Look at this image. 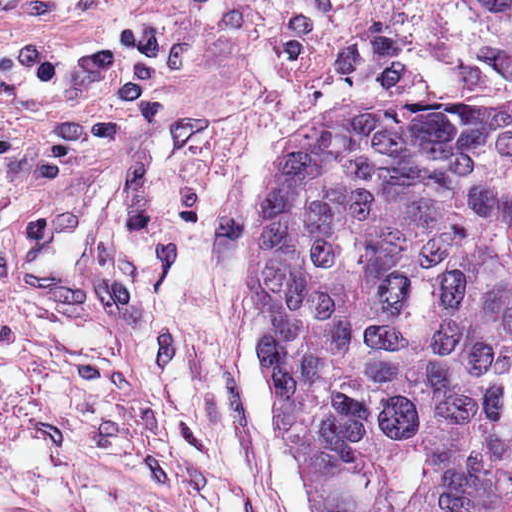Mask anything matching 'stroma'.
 Returning a JSON list of instances; mask_svg holds the SVG:
<instances>
[{
	"label": "stroma",
	"instance_id": "35a3bbf8",
	"mask_svg": "<svg viewBox=\"0 0 512 512\" xmlns=\"http://www.w3.org/2000/svg\"><path fill=\"white\" fill-rule=\"evenodd\" d=\"M512 95L453 0H0V512H315L267 198L333 97Z\"/></svg>",
	"mask_w": 512,
	"mask_h": 512
}]
</instances>
